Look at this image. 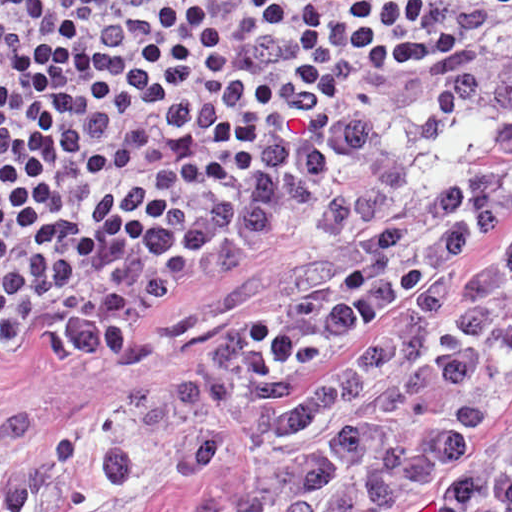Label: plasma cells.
<instances>
[{
  "label": "plasma cells",
  "mask_w": 512,
  "mask_h": 512,
  "mask_svg": "<svg viewBox=\"0 0 512 512\" xmlns=\"http://www.w3.org/2000/svg\"><path fill=\"white\" fill-rule=\"evenodd\" d=\"M398 106L310 215L329 280L173 372L96 380L14 512H127L254 419L241 512H512V242L458 280L512 199V37Z\"/></svg>",
  "instance_id": "plasma-cells-1"
}]
</instances>
